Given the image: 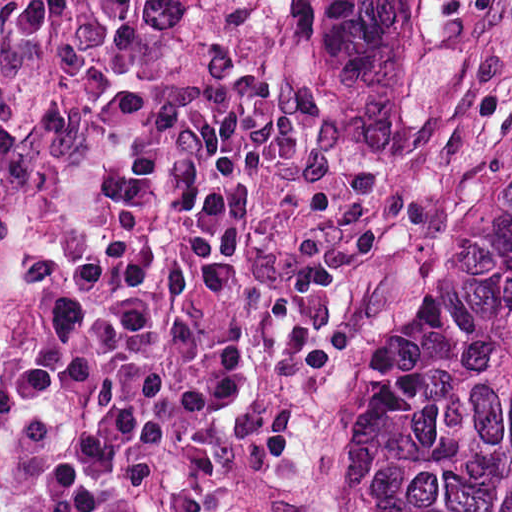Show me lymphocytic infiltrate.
I'll return each mask as SVG.
<instances>
[{
	"label": "lymphocytic infiltrate",
	"instance_id": "obj_1",
	"mask_svg": "<svg viewBox=\"0 0 512 512\" xmlns=\"http://www.w3.org/2000/svg\"><path fill=\"white\" fill-rule=\"evenodd\" d=\"M416 279L411 203L285 107L246 83L146 99L6 255L0 512H306Z\"/></svg>",
	"mask_w": 512,
	"mask_h": 512
}]
</instances>
